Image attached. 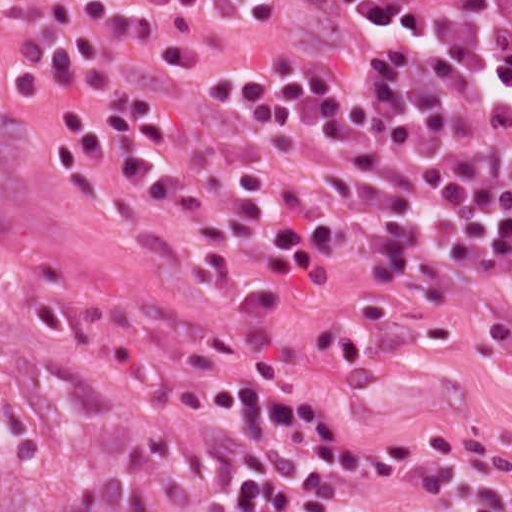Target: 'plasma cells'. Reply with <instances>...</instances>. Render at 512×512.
I'll return each mask as SVG.
<instances>
[{"instance_id": "1", "label": "plasma cells", "mask_w": 512, "mask_h": 512, "mask_svg": "<svg viewBox=\"0 0 512 512\" xmlns=\"http://www.w3.org/2000/svg\"><path fill=\"white\" fill-rule=\"evenodd\" d=\"M0 87L227 288L363 259L362 301L482 317L512 357V0H33ZM281 379L231 408L222 512H357L367 446ZM434 462L414 512H512V433Z\"/></svg>"}]
</instances>
